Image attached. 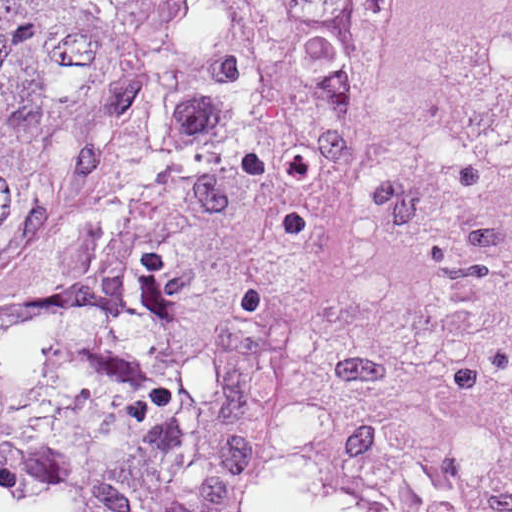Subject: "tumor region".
Listing matches in <instances>:
<instances>
[{"instance_id": "1", "label": "tumor region", "mask_w": 512, "mask_h": 512, "mask_svg": "<svg viewBox=\"0 0 512 512\" xmlns=\"http://www.w3.org/2000/svg\"><path fill=\"white\" fill-rule=\"evenodd\" d=\"M388 0H0V512H266Z\"/></svg>"}]
</instances>
